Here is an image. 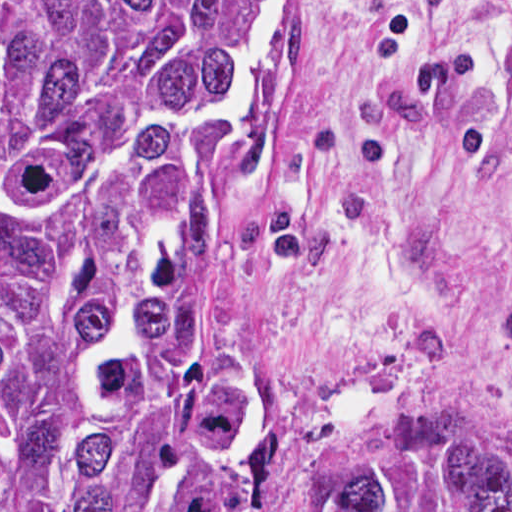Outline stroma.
I'll use <instances>...</instances> for the list:
<instances>
[{"label": "stroma", "instance_id": "obj_1", "mask_svg": "<svg viewBox=\"0 0 512 512\" xmlns=\"http://www.w3.org/2000/svg\"><path fill=\"white\" fill-rule=\"evenodd\" d=\"M396 2L410 55L372 0H278L203 276L214 385L253 450L512 473V0Z\"/></svg>", "mask_w": 512, "mask_h": 512}]
</instances>
